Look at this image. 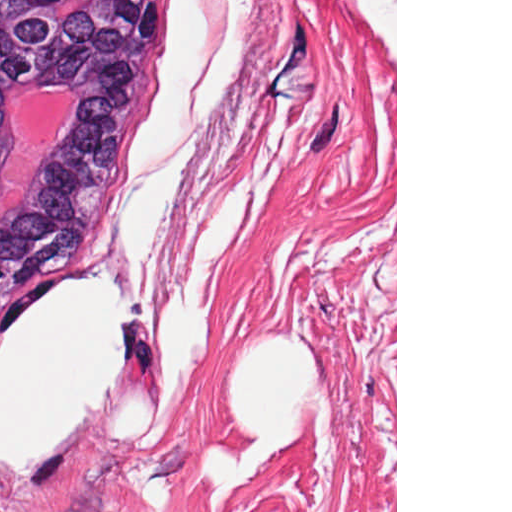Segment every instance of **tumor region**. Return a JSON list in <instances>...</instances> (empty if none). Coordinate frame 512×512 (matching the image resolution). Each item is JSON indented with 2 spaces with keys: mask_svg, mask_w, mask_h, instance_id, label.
<instances>
[{
  "mask_svg": "<svg viewBox=\"0 0 512 512\" xmlns=\"http://www.w3.org/2000/svg\"><path fill=\"white\" fill-rule=\"evenodd\" d=\"M165 0H0V164L26 94L76 106L0 221V323L75 241L155 59Z\"/></svg>",
  "mask_w": 512,
  "mask_h": 512,
  "instance_id": "1",
  "label": "tumor region"
}]
</instances>
